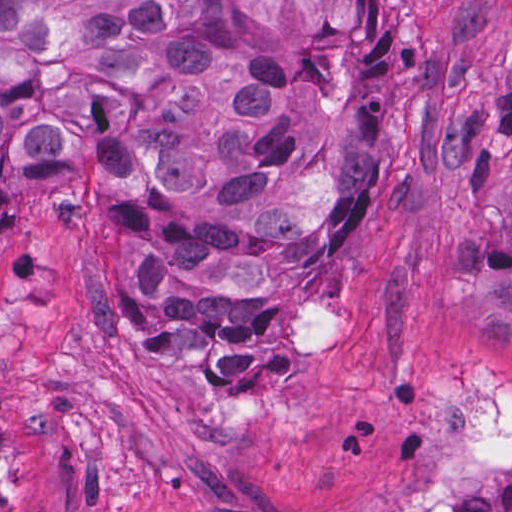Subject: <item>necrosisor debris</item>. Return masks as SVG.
Here are the masks:
<instances>
[{
	"instance_id": "1",
	"label": "necrosis or debris",
	"mask_w": 512,
	"mask_h": 512,
	"mask_svg": "<svg viewBox=\"0 0 512 512\" xmlns=\"http://www.w3.org/2000/svg\"><path fill=\"white\" fill-rule=\"evenodd\" d=\"M442 463L453 500L418 493L393 512H512V392L452 389Z\"/></svg>"
}]
</instances>
